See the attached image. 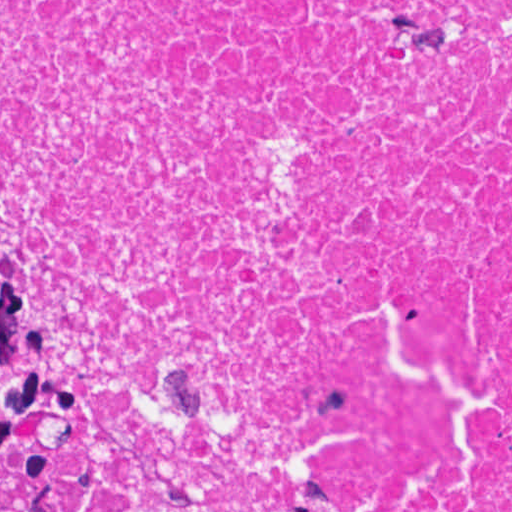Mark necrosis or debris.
<instances>
[{"instance_id":"1","label":"necrosis or debris","mask_w":512,"mask_h":512,"mask_svg":"<svg viewBox=\"0 0 512 512\" xmlns=\"http://www.w3.org/2000/svg\"><path fill=\"white\" fill-rule=\"evenodd\" d=\"M0 273L77 512H512V0H0Z\"/></svg>"}]
</instances>
